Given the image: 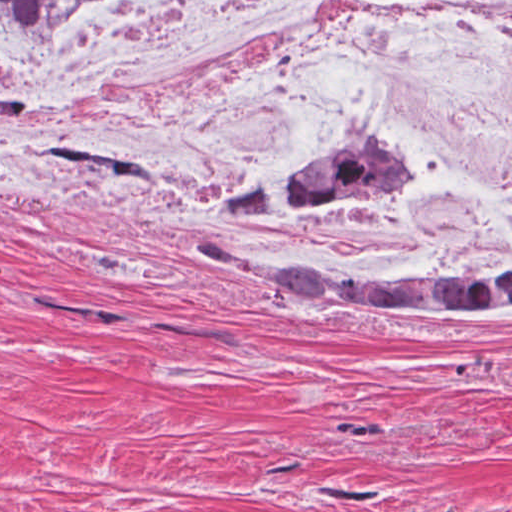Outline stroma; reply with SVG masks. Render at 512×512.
Instances as JSON below:
<instances>
[{
	"mask_svg": "<svg viewBox=\"0 0 512 512\" xmlns=\"http://www.w3.org/2000/svg\"><path fill=\"white\" fill-rule=\"evenodd\" d=\"M414 158L416 185L374 200L420 192ZM342 211L154 204L0 163V512H512V303L337 307L192 244L354 283L512 257L372 259L314 225Z\"/></svg>",
	"mask_w": 512,
	"mask_h": 512,
	"instance_id": "obj_1",
	"label": "stroma"
}]
</instances>
